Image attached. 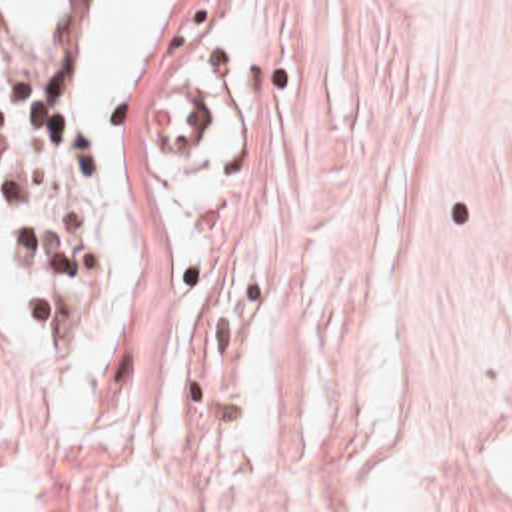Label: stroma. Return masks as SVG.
I'll return each mask as SVG.
<instances>
[{"instance_id":"obj_1","label":"stroma","mask_w":512,"mask_h":512,"mask_svg":"<svg viewBox=\"0 0 512 512\" xmlns=\"http://www.w3.org/2000/svg\"><path fill=\"white\" fill-rule=\"evenodd\" d=\"M94 0H76L84 120ZM149 228L127 344L48 416L0 332V442L64 512H512V0H165L121 98Z\"/></svg>"}]
</instances>
